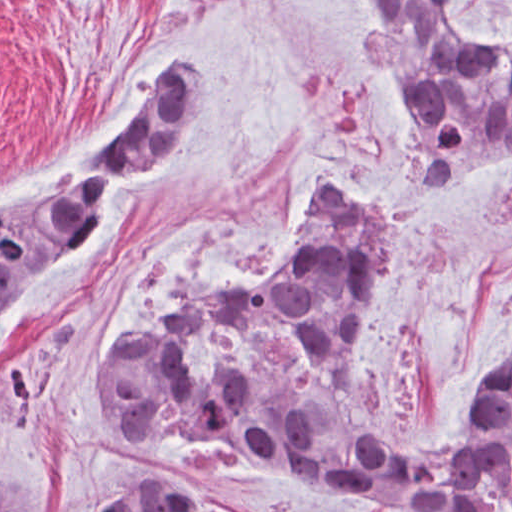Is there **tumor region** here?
Listing matches in <instances>:
<instances>
[{"label":"tumor region","instance_id":"obj_1","mask_svg":"<svg viewBox=\"0 0 512 512\" xmlns=\"http://www.w3.org/2000/svg\"><path fill=\"white\" fill-rule=\"evenodd\" d=\"M451 0H353L361 30L409 113L411 197L489 161H512V41L474 47L450 23ZM138 126L66 182L0 204V347L37 296L124 203L204 132L214 68L196 52ZM401 232L353 188L306 201L284 268L249 291L191 286L174 320L103 348L99 404L123 441L197 435L234 456L320 476L411 512H489L512 482V351L474 400L464 435L389 441L364 414L356 372L368 321ZM246 317L292 323L330 362L335 395L310 402L263 364L208 375L185 346ZM133 492L108 512H256L185 466L122 473ZM29 481L0 464V512H37Z\"/></svg>","mask_w":512,"mask_h":512}]
</instances>
